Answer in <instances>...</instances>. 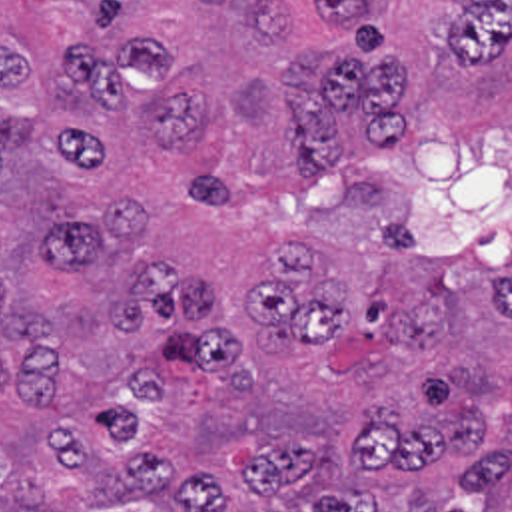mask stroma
Segmentation results:
<instances>
[{
  "mask_svg": "<svg viewBox=\"0 0 512 512\" xmlns=\"http://www.w3.org/2000/svg\"><path fill=\"white\" fill-rule=\"evenodd\" d=\"M372 14L402 44L404 112L480 108L512 118V52L490 66L458 68L444 44L452 0H372Z\"/></svg>",
  "mask_w": 512,
  "mask_h": 512,
  "instance_id": "stroma-1",
  "label": "stroma"
}]
</instances>
